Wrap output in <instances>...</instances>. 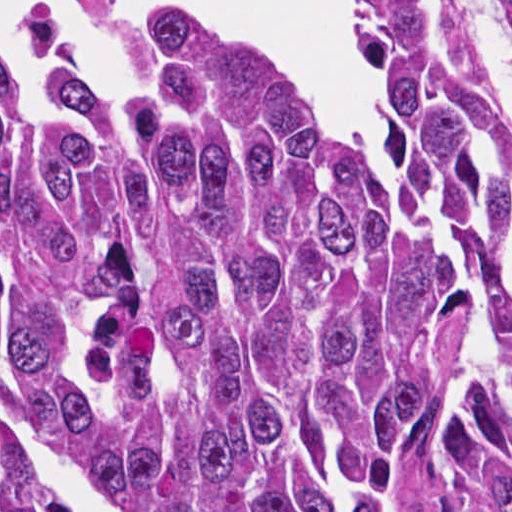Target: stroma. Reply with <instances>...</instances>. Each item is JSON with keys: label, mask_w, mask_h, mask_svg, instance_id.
<instances>
[{"label": "stroma", "mask_w": 512, "mask_h": 512, "mask_svg": "<svg viewBox=\"0 0 512 512\" xmlns=\"http://www.w3.org/2000/svg\"><path fill=\"white\" fill-rule=\"evenodd\" d=\"M455 32L483 94L494 110L512 120V61L485 30L473 0H451Z\"/></svg>", "instance_id": "stroma-1"}]
</instances>
